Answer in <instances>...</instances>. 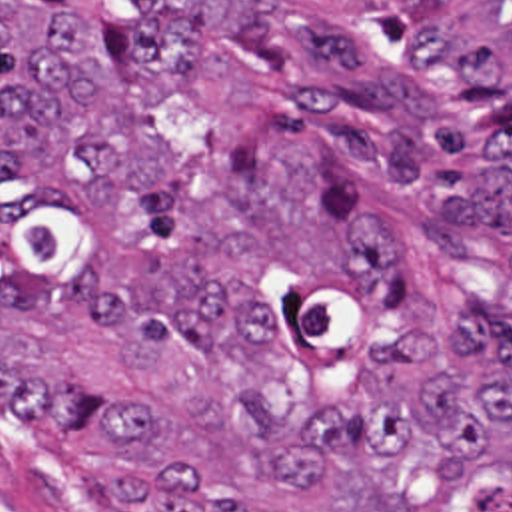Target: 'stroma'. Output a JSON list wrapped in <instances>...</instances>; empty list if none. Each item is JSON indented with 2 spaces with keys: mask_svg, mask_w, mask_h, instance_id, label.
Here are the masks:
<instances>
[{
  "mask_svg": "<svg viewBox=\"0 0 512 512\" xmlns=\"http://www.w3.org/2000/svg\"><path fill=\"white\" fill-rule=\"evenodd\" d=\"M0 491L47 512H109L51 433L2 389Z\"/></svg>",
  "mask_w": 512,
  "mask_h": 512,
  "instance_id": "stroma-1",
  "label": "stroma"
}]
</instances>
